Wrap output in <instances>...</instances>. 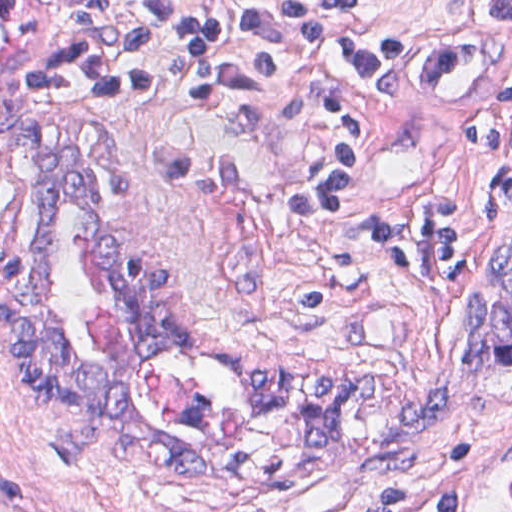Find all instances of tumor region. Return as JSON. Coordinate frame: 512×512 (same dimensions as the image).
I'll list each match as a JSON object with an SVG mask.
<instances>
[{"label": "tumor region", "instance_id": "e687c5a6", "mask_svg": "<svg viewBox=\"0 0 512 512\" xmlns=\"http://www.w3.org/2000/svg\"><path fill=\"white\" fill-rule=\"evenodd\" d=\"M7 169L1 222V329L21 381L37 385L62 408V420L48 430L47 445L62 460H76L107 446L145 466L179 478H205L214 463L204 454L162 440L139 418L124 388L78 362L64 341L51 293L55 251L48 225L54 201L74 199L93 220L97 242L115 268L118 315L127 335L152 345H190L220 359L244 397L265 404L277 400L306 414L302 455L341 438L351 406L378 393V380L308 382L252 373L219 355L174 312L175 285L162 268L125 253L109 230L95 182V158L81 145L50 144L31 118L14 120L1 138Z\"/></svg>", "mask_w": 512, "mask_h": 512}]
</instances>
